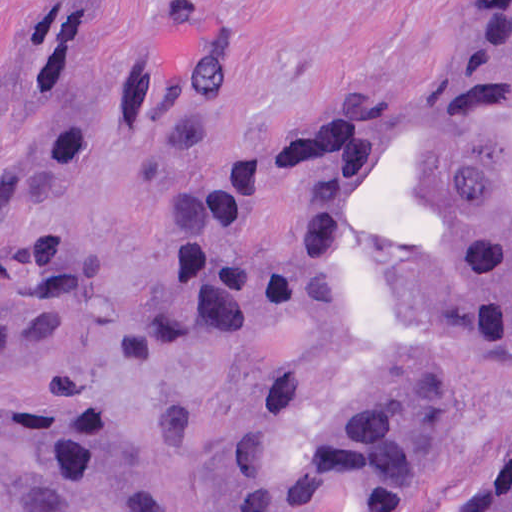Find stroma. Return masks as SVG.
<instances>
[{"label": "stroma", "instance_id": "35a3bbf8", "mask_svg": "<svg viewBox=\"0 0 512 512\" xmlns=\"http://www.w3.org/2000/svg\"><path fill=\"white\" fill-rule=\"evenodd\" d=\"M120 1L85 58L99 82L154 67L196 37L243 48V88L222 120L161 155L89 137L58 174L2 202L0 233L85 271L80 323L22 375L113 414L154 484V512H223L257 448L266 345L189 364L137 354V326L165 282V251L208 185L298 124L420 100L475 54L512 0H0V85L30 47L39 3ZM24 132L0 137V162ZM512 457V407L440 476L462 512ZM103 512V511H89ZM354 512V511H330Z\"/></svg>", "mask_w": 512, "mask_h": 512}]
</instances>
